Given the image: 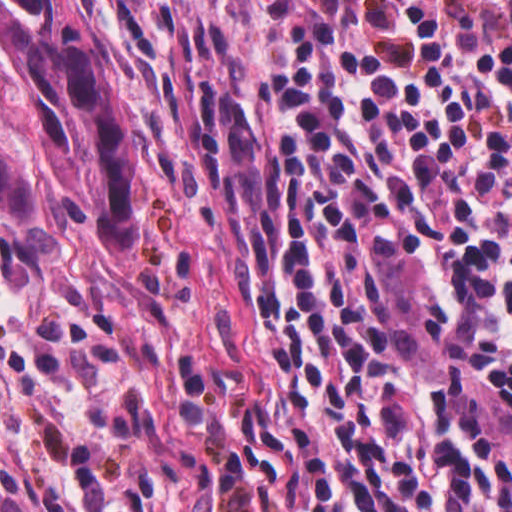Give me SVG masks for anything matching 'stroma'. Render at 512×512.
Instances as JSON below:
<instances>
[{
	"mask_svg": "<svg viewBox=\"0 0 512 512\" xmlns=\"http://www.w3.org/2000/svg\"><path fill=\"white\" fill-rule=\"evenodd\" d=\"M140 114L139 202L127 251L0 204V480L43 512H242L188 432L193 374L254 378L247 266L181 166L127 0H90ZM0 126L33 110L0 53Z\"/></svg>",
	"mask_w": 512,
	"mask_h": 512,
	"instance_id": "35a3bbf8",
	"label": "stroma"
}]
</instances>
